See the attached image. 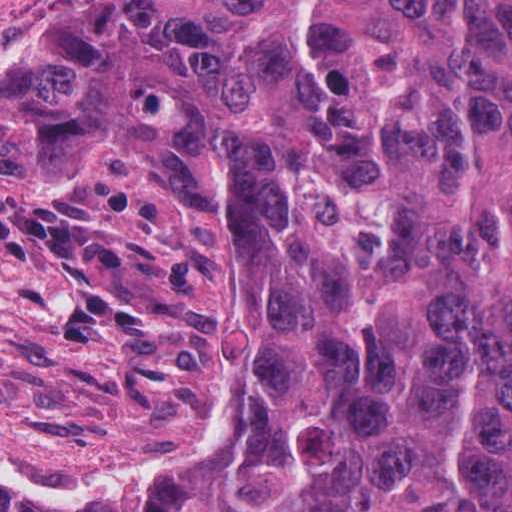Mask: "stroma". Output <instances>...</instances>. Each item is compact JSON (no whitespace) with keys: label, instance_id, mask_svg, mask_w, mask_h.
Returning a JSON list of instances; mask_svg holds the SVG:
<instances>
[{"label":"stroma","instance_id":"stroma-1","mask_svg":"<svg viewBox=\"0 0 512 512\" xmlns=\"http://www.w3.org/2000/svg\"><path fill=\"white\" fill-rule=\"evenodd\" d=\"M97 1L0 0V69ZM220 238L179 183L148 170L0 159L1 464L132 470L236 385L248 408L183 484L261 430L268 409L227 306Z\"/></svg>","mask_w":512,"mask_h":512}]
</instances>
